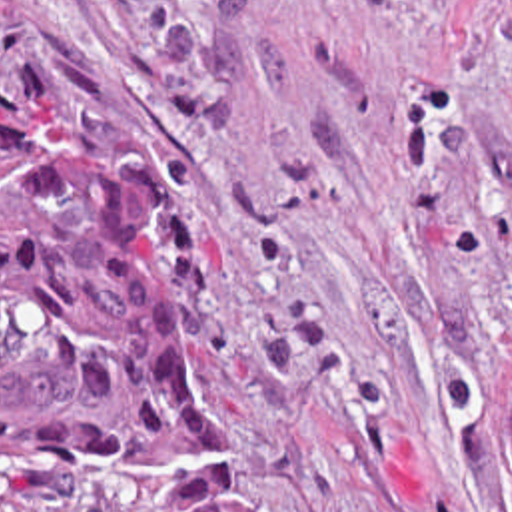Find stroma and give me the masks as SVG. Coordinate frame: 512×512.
<instances>
[{
    "label": "stroma",
    "instance_id": "obj_1",
    "mask_svg": "<svg viewBox=\"0 0 512 512\" xmlns=\"http://www.w3.org/2000/svg\"><path fill=\"white\" fill-rule=\"evenodd\" d=\"M0 85L132 208L266 512H512V0H0Z\"/></svg>",
    "mask_w": 512,
    "mask_h": 512
}]
</instances>
